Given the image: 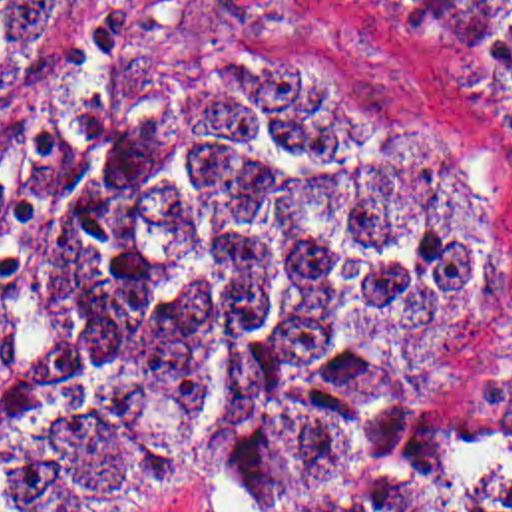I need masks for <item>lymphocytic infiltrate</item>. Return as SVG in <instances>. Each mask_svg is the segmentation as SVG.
Returning a JSON list of instances; mask_svg holds the SVG:
<instances>
[{
	"instance_id": "f902f5d3",
	"label": "lymphocytic infiltrate",
	"mask_w": 512,
	"mask_h": 512,
	"mask_svg": "<svg viewBox=\"0 0 512 512\" xmlns=\"http://www.w3.org/2000/svg\"><path fill=\"white\" fill-rule=\"evenodd\" d=\"M19 187V169L7 167L0 171V199L3 195L15 191Z\"/></svg>"
}]
</instances>
